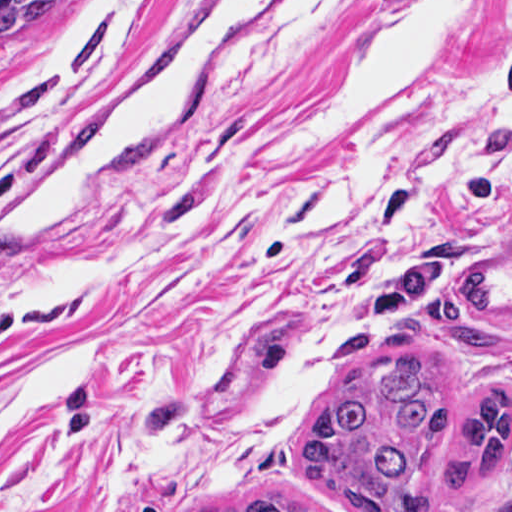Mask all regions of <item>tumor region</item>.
<instances>
[{
  "label": "tumor region",
  "instance_id": "e687c5a6",
  "mask_svg": "<svg viewBox=\"0 0 512 512\" xmlns=\"http://www.w3.org/2000/svg\"><path fill=\"white\" fill-rule=\"evenodd\" d=\"M86 0H0V53L53 40L80 18ZM459 309L444 298L418 301L419 328L478 349L498 346V307L483 267L455 284ZM509 387L495 382L461 412L439 393L429 360L413 354L373 367L337 387L301 444L309 479L360 512L436 511L442 485L461 493L504 477ZM200 512H311L278 496L223 500Z\"/></svg>",
  "mask_w": 512,
  "mask_h": 512
}]
</instances>
